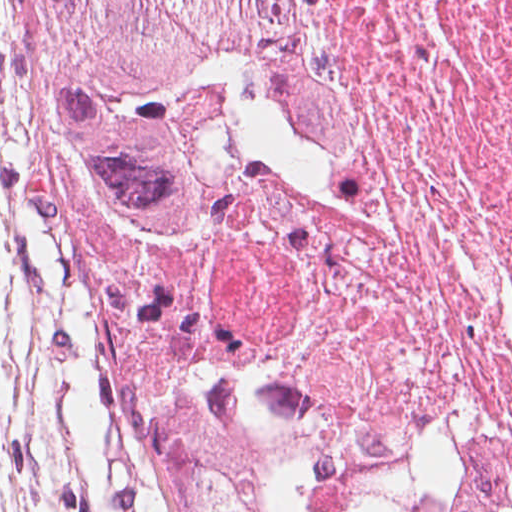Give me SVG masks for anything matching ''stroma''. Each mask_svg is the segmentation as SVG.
Here are the masks:
<instances>
[{"label":"stroma","instance_id":"stroma-1","mask_svg":"<svg viewBox=\"0 0 512 512\" xmlns=\"http://www.w3.org/2000/svg\"><path fill=\"white\" fill-rule=\"evenodd\" d=\"M33 31L0 0V512H110L119 472L36 224Z\"/></svg>","mask_w":512,"mask_h":512}]
</instances>
